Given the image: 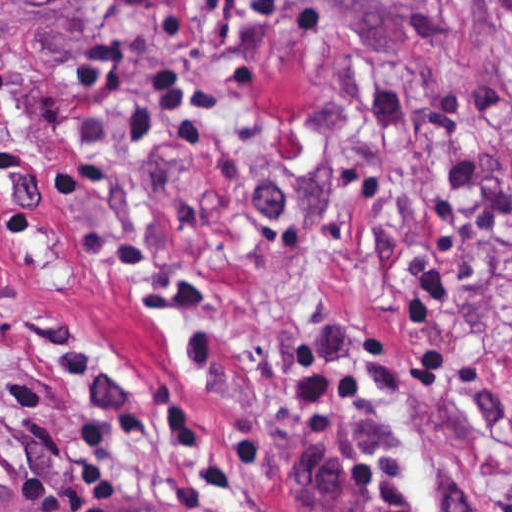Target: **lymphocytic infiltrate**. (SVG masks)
<instances>
[{"mask_svg":"<svg viewBox=\"0 0 512 512\" xmlns=\"http://www.w3.org/2000/svg\"><path fill=\"white\" fill-rule=\"evenodd\" d=\"M6 363V338L0 328V376ZM0 512H64L54 483L40 478H11L0 484Z\"/></svg>","mask_w":512,"mask_h":512,"instance_id":"1","label":"lymphocytic infiltrate"}]
</instances>
